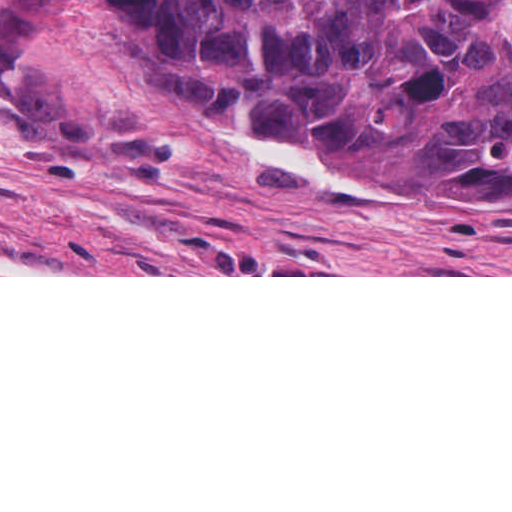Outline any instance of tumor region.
<instances>
[{
    "mask_svg": "<svg viewBox=\"0 0 512 512\" xmlns=\"http://www.w3.org/2000/svg\"><path fill=\"white\" fill-rule=\"evenodd\" d=\"M80 13L120 20L141 101L36 58ZM0 93L87 119L158 107L442 212L512 202V0H0Z\"/></svg>",
    "mask_w": 512,
    "mask_h": 512,
    "instance_id": "e687c5a6",
    "label": "tumor region"
}]
</instances>
